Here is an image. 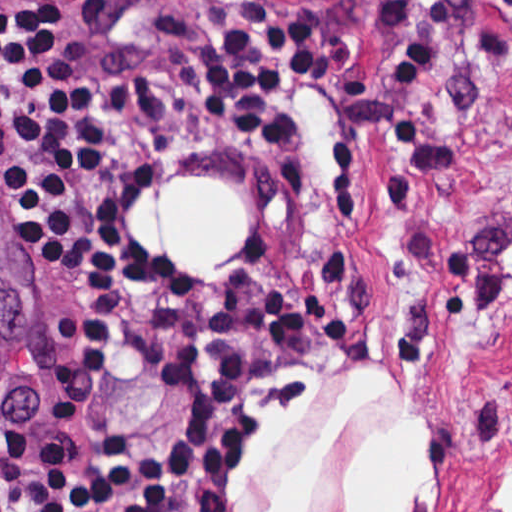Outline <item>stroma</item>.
Here are the masks:
<instances>
[{"label": "stroma", "instance_id": "35a3bbf8", "mask_svg": "<svg viewBox=\"0 0 512 512\" xmlns=\"http://www.w3.org/2000/svg\"><path fill=\"white\" fill-rule=\"evenodd\" d=\"M93 129L125 198L156 178L225 176L250 194V242L220 287L297 293L248 381L213 512H264L340 416L296 512H346L356 455L419 429L430 455L402 512H494L512 472V0H64ZM275 3L334 50L298 91L302 169L198 121L184 64L237 5ZM80 288L16 232L0 176V427H31Z\"/></svg>", "mask_w": 512, "mask_h": 512}]
</instances>
